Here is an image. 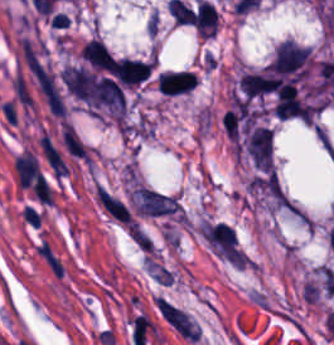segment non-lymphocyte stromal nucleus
<instances>
[{
    "label": "non-lymphocyte stromal nucleus",
    "mask_w": 334,
    "mask_h": 345,
    "mask_svg": "<svg viewBox=\"0 0 334 345\" xmlns=\"http://www.w3.org/2000/svg\"><path fill=\"white\" fill-rule=\"evenodd\" d=\"M94 199L98 209L111 222L133 235L140 232L127 201L115 192L109 188L96 185Z\"/></svg>",
    "instance_id": "1"
},
{
    "label": "non-lymphocyte stromal nucleus",
    "mask_w": 334,
    "mask_h": 345,
    "mask_svg": "<svg viewBox=\"0 0 334 345\" xmlns=\"http://www.w3.org/2000/svg\"><path fill=\"white\" fill-rule=\"evenodd\" d=\"M32 251L45 269L60 280L67 275L66 263L47 236L34 239Z\"/></svg>",
    "instance_id": "2"
},
{
    "label": "non-lymphocyte stromal nucleus",
    "mask_w": 334,
    "mask_h": 345,
    "mask_svg": "<svg viewBox=\"0 0 334 345\" xmlns=\"http://www.w3.org/2000/svg\"><path fill=\"white\" fill-rule=\"evenodd\" d=\"M157 308L164 320L182 337L197 340L196 330L188 316L163 297L157 299Z\"/></svg>",
    "instance_id": "3"
}]
</instances>
